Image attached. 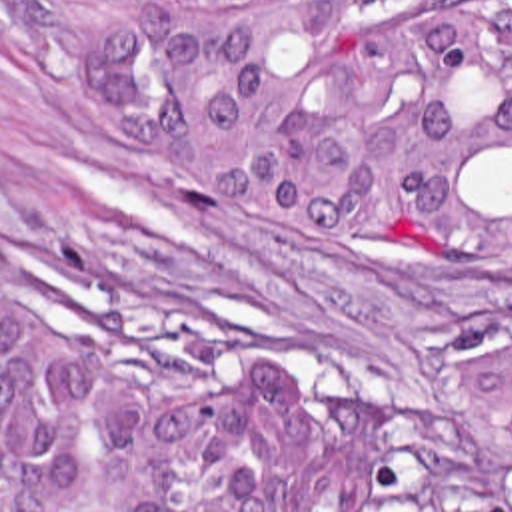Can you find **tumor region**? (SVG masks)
I'll return each mask as SVG.
<instances>
[{"label":"tumor region","instance_id":"e687c5a6","mask_svg":"<svg viewBox=\"0 0 512 512\" xmlns=\"http://www.w3.org/2000/svg\"><path fill=\"white\" fill-rule=\"evenodd\" d=\"M208 205L512 253V0H12ZM390 410L198 382L0 265V512H392ZM430 512H512V345L434 404Z\"/></svg>","mask_w":512,"mask_h":512}]
</instances>
